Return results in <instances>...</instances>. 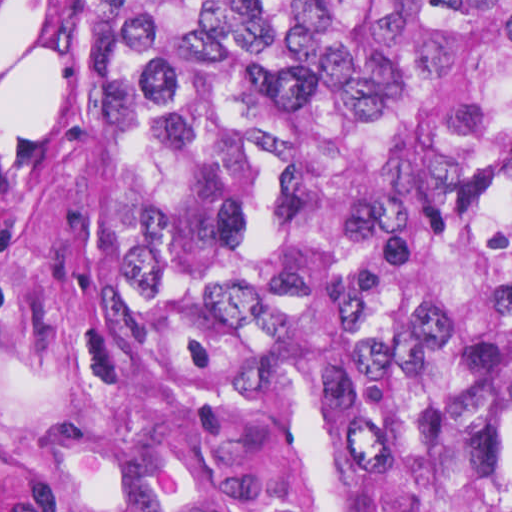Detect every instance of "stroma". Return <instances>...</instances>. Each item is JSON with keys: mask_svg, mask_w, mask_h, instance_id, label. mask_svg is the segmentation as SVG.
I'll use <instances>...</instances> for the list:
<instances>
[{"mask_svg": "<svg viewBox=\"0 0 512 512\" xmlns=\"http://www.w3.org/2000/svg\"><path fill=\"white\" fill-rule=\"evenodd\" d=\"M89 1L0 0V512H331L300 424L214 408L108 333L100 133L72 93Z\"/></svg>", "mask_w": 512, "mask_h": 512, "instance_id": "stroma-1", "label": "stroma"}]
</instances>
